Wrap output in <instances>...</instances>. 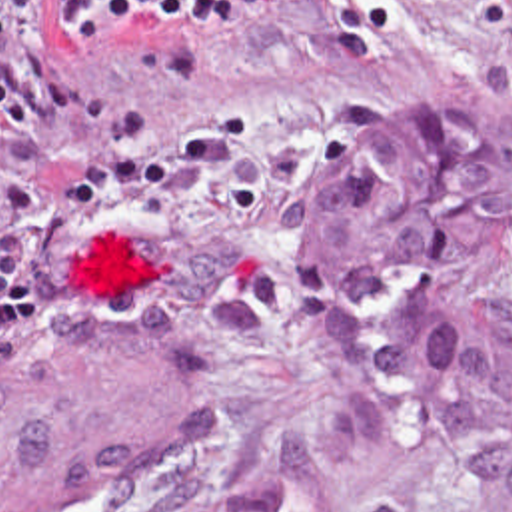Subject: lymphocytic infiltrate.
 Returning <instances> with one entry per match:
<instances>
[{"mask_svg":"<svg viewBox=\"0 0 512 512\" xmlns=\"http://www.w3.org/2000/svg\"><path fill=\"white\" fill-rule=\"evenodd\" d=\"M253 0H55L73 28H123L149 16H171L201 32L239 18ZM93 96L53 72L37 34L0 18V126H31L37 112L81 108Z\"/></svg>","mask_w":512,"mask_h":512,"instance_id":"lymphocytic-infiltrate-1","label":"lymphocytic infiltrate"}]
</instances>
